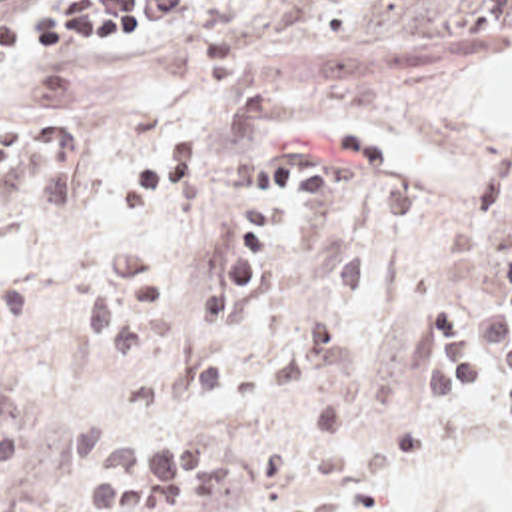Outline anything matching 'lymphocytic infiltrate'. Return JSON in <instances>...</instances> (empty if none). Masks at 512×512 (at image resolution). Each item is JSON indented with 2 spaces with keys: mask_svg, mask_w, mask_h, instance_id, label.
<instances>
[{
  "mask_svg": "<svg viewBox=\"0 0 512 512\" xmlns=\"http://www.w3.org/2000/svg\"><path fill=\"white\" fill-rule=\"evenodd\" d=\"M29 0H0V69L23 51H91L109 37L127 39L143 19H177L202 1L55 0L45 13L9 15ZM200 127L186 123L123 173H101L85 159V123L77 113L47 111L0 127V209L59 217L95 197L125 201L143 215L145 237L109 247L101 265L77 277L73 303L105 353H147L184 329L173 309L190 301L194 323L228 329L256 291L268 257L298 217L346 219L390 227L412 219V183L392 149L372 133L344 131L322 143H288L260 167L248 219L216 273L165 279L155 251L167 215L206 175ZM460 317L438 311L434 335L410 353L412 389L456 409L466 389H484L512 407V373L480 367L460 343Z\"/></svg>",
  "mask_w": 512,
  "mask_h": 512,
  "instance_id": "obj_1",
  "label": "lymphocytic infiltrate"
}]
</instances>
